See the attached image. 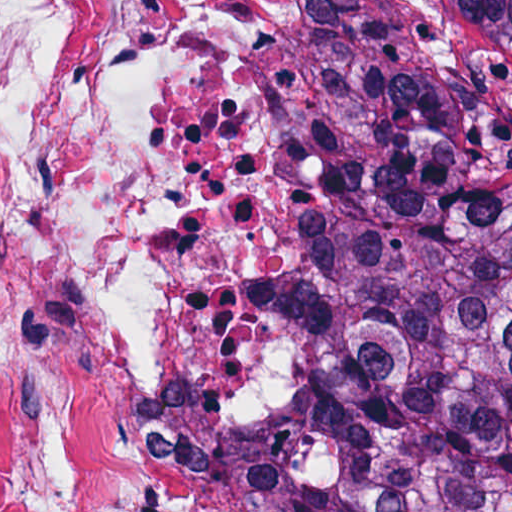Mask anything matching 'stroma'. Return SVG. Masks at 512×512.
<instances>
[{
	"label": "stroma",
	"mask_w": 512,
	"mask_h": 512,
	"mask_svg": "<svg viewBox=\"0 0 512 512\" xmlns=\"http://www.w3.org/2000/svg\"><path fill=\"white\" fill-rule=\"evenodd\" d=\"M369 2L309 0L297 48V106L311 176V227L275 322L276 402L207 491L273 437L304 388L327 332L359 217L369 144Z\"/></svg>",
	"instance_id": "1"
}]
</instances>
